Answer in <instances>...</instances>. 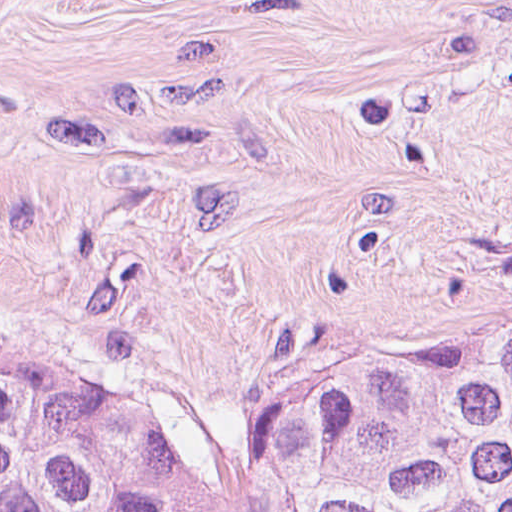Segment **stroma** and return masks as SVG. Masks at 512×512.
<instances>
[{"mask_svg":"<svg viewBox=\"0 0 512 512\" xmlns=\"http://www.w3.org/2000/svg\"><path fill=\"white\" fill-rule=\"evenodd\" d=\"M512 327V0H0V361L203 460Z\"/></svg>","mask_w":512,"mask_h":512,"instance_id":"1","label":"stroma"}]
</instances>
